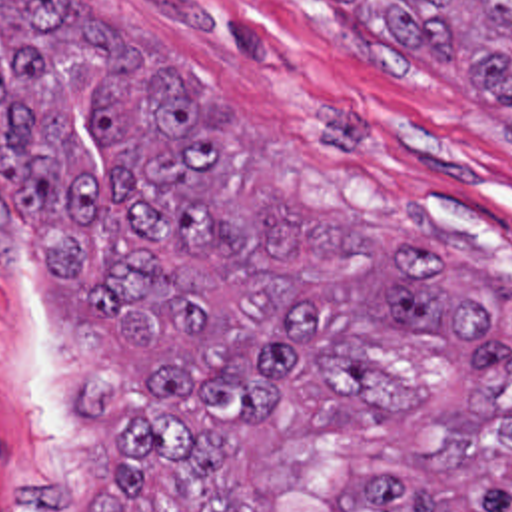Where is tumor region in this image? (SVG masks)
<instances>
[{"mask_svg": "<svg viewBox=\"0 0 512 512\" xmlns=\"http://www.w3.org/2000/svg\"><path fill=\"white\" fill-rule=\"evenodd\" d=\"M323 1L512 141V0ZM0 227L145 377L121 512H512V279L405 221L231 205L199 81L65 0H0Z\"/></svg>", "mask_w": 512, "mask_h": 512, "instance_id": "tumor-region-1", "label": "tumor region"}]
</instances>
